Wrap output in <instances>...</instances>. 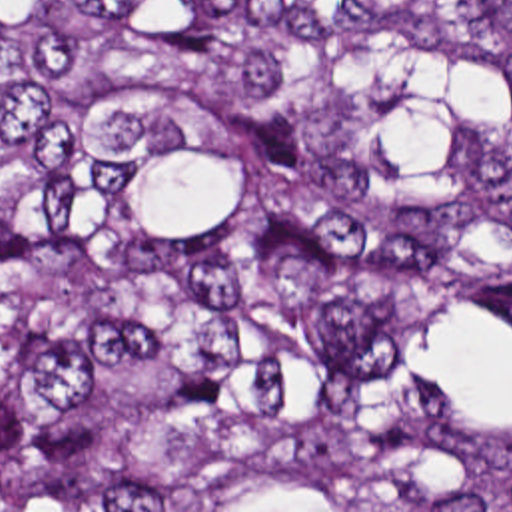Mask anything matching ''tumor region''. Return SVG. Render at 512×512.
Here are the masks:
<instances>
[{"label": "tumor region", "mask_w": 512, "mask_h": 512, "mask_svg": "<svg viewBox=\"0 0 512 512\" xmlns=\"http://www.w3.org/2000/svg\"><path fill=\"white\" fill-rule=\"evenodd\" d=\"M0 512H512V0H0Z\"/></svg>", "instance_id": "e687c5a6"}]
</instances>
